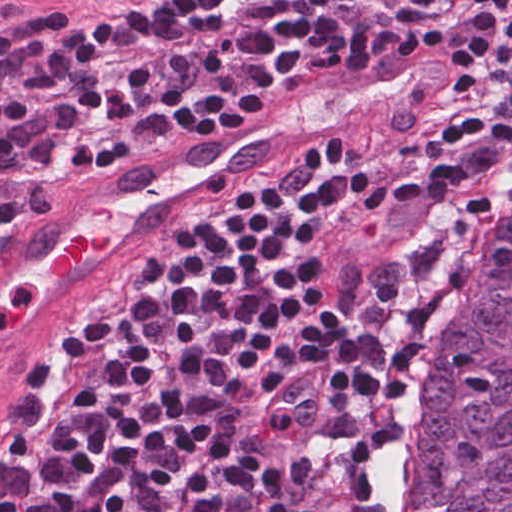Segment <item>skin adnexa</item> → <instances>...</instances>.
Here are the masks:
<instances>
[{
    "instance_id": "bc48264e",
    "label": "skin adnexa",
    "mask_w": 512,
    "mask_h": 512,
    "mask_svg": "<svg viewBox=\"0 0 512 512\" xmlns=\"http://www.w3.org/2000/svg\"><path fill=\"white\" fill-rule=\"evenodd\" d=\"M386 512H512V239L453 327L428 411L397 439Z\"/></svg>"
}]
</instances>
